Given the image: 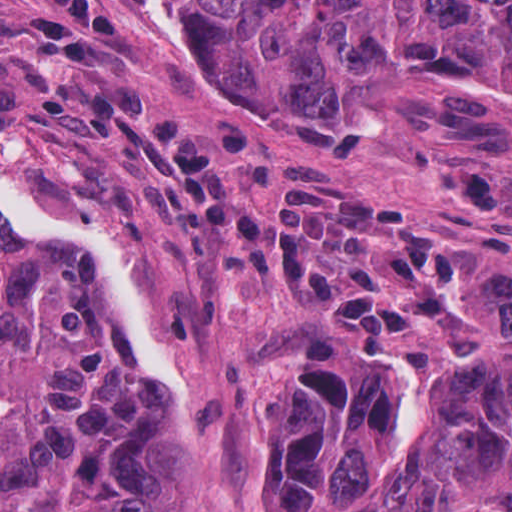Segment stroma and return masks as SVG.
<instances>
[{
    "label": "stroma",
    "instance_id": "35a3bbf8",
    "mask_svg": "<svg viewBox=\"0 0 512 512\" xmlns=\"http://www.w3.org/2000/svg\"><path fill=\"white\" fill-rule=\"evenodd\" d=\"M24 1L0 0V170L38 204L114 233L134 257L186 369L181 424L198 455L205 512H261V387L276 336L292 328L328 333L408 370L399 420L409 450L428 421L435 370L484 356L501 332V297L512 284V126L450 88L414 86L345 105L230 65L162 0H113L118 36L104 77L140 78L182 131L212 119L243 124L252 143L238 188L257 215L270 208L274 162L299 157L389 191L474 259L464 306L421 337L371 350L304 295L252 279L203 280L187 265L177 210L128 156L81 144L73 114L39 113V81L11 41ZM384 496L372 512H383ZM458 512L512 507L476 500Z\"/></svg>",
    "mask_w": 512,
    "mask_h": 512
}]
</instances>
